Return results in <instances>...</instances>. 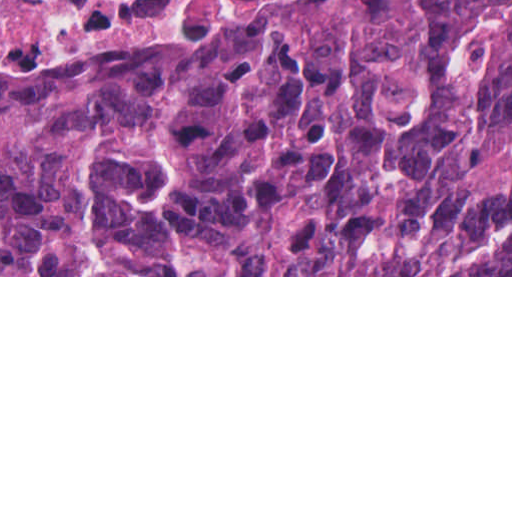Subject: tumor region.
<instances>
[{"label":"tumor region","mask_w":512,"mask_h":512,"mask_svg":"<svg viewBox=\"0 0 512 512\" xmlns=\"http://www.w3.org/2000/svg\"><path fill=\"white\" fill-rule=\"evenodd\" d=\"M0 275H512V0L0 67Z\"/></svg>","instance_id":"e687c5a6"}]
</instances>
